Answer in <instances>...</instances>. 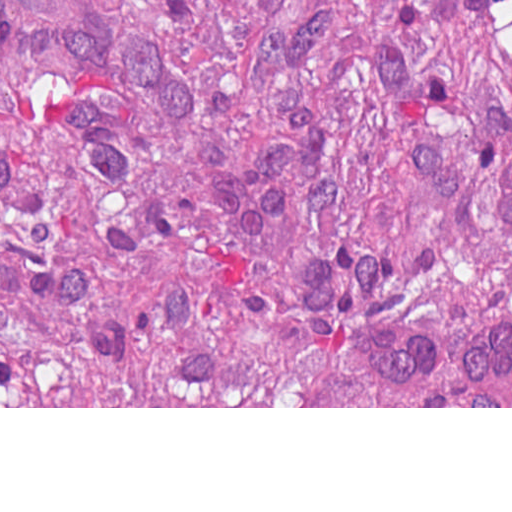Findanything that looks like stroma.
Segmentation results:
<instances>
[{"label":"stroma","mask_w":512,"mask_h":512,"mask_svg":"<svg viewBox=\"0 0 512 512\" xmlns=\"http://www.w3.org/2000/svg\"><path fill=\"white\" fill-rule=\"evenodd\" d=\"M0 408H512V406H1V0H0Z\"/></svg>","instance_id":"stroma-1"}]
</instances>
